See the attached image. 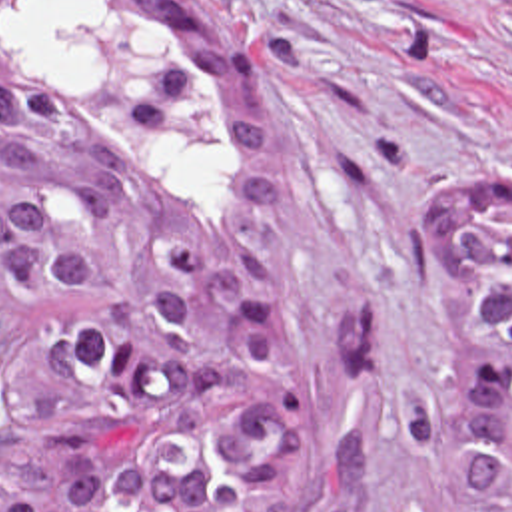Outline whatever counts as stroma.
Returning <instances> with one entry per match:
<instances>
[{
  "label": "stroma",
  "mask_w": 512,
  "mask_h": 512,
  "mask_svg": "<svg viewBox=\"0 0 512 512\" xmlns=\"http://www.w3.org/2000/svg\"><path fill=\"white\" fill-rule=\"evenodd\" d=\"M257 55L289 205L287 315L319 384L331 472L369 436V512H452L385 416L440 369L424 217L512 179V0H205Z\"/></svg>",
  "instance_id": "obj_1"
}]
</instances>
